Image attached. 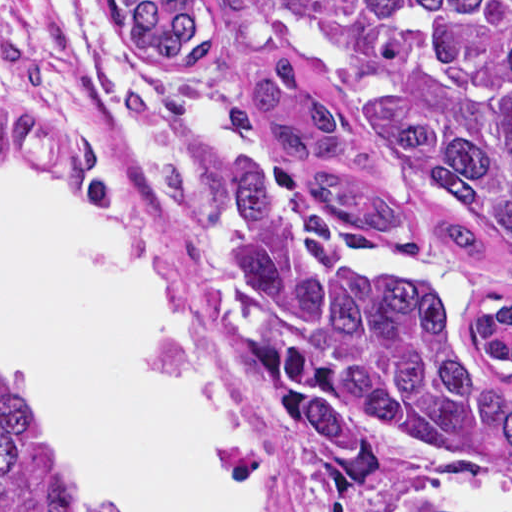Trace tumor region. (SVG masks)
I'll return each mask as SVG.
<instances>
[{
  "label": "tumor region",
  "instance_id": "e687c5a6",
  "mask_svg": "<svg viewBox=\"0 0 512 512\" xmlns=\"http://www.w3.org/2000/svg\"><path fill=\"white\" fill-rule=\"evenodd\" d=\"M334 61L350 116L389 180L436 214L444 243L512 259V0H247ZM127 46L159 72L208 82L222 56L211 0H115ZM251 92L300 171L248 165L223 273L256 333L255 386L286 444L334 492L374 496L388 441L512 469V392L467 348L433 275L389 272L348 232L398 233L358 163L327 77L282 57ZM0 87L2 69L0 65ZM475 335L512 370V302ZM0 512H44L35 447L0 378Z\"/></svg>",
  "mask_w": 512,
  "mask_h": 512
}]
</instances>
